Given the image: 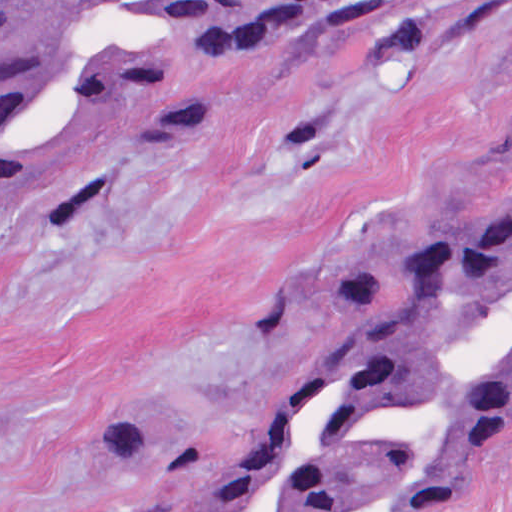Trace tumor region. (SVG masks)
Masks as SVG:
<instances>
[{
	"instance_id": "1",
	"label": "tumor region",
	"mask_w": 512,
	"mask_h": 512,
	"mask_svg": "<svg viewBox=\"0 0 512 512\" xmlns=\"http://www.w3.org/2000/svg\"><path fill=\"white\" fill-rule=\"evenodd\" d=\"M335 0H0V188L31 178L36 106L143 95L155 138L203 103L164 57L77 37L109 18L202 54L275 44ZM512 434V148L381 279L338 293L273 378L248 439L205 463L117 422L130 512H442Z\"/></svg>"
}]
</instances>
